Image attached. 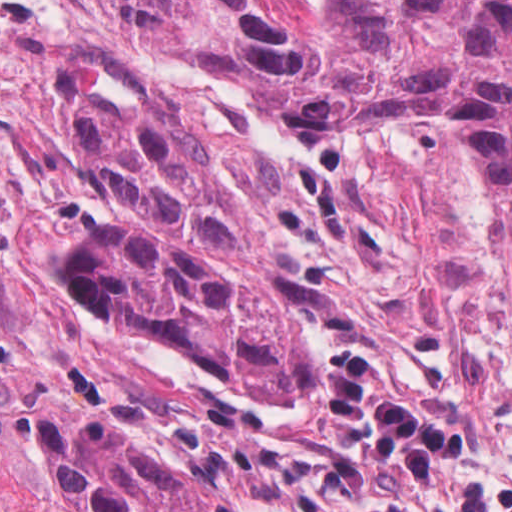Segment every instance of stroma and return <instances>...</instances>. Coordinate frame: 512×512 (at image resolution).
<instances>
[{
	"mask_svg": "<svg viewBox=\"0 0 512 512\" xmlns=\"http://www.w3.org/2000/svg\"><path fill=\"white\" fill-rule=\"evenodd\" d=\"M80 92H164L199 110L285 208L269 253L312 344L305 398L226 386L131 332L223 493L245 512H352L402 499L409 473L370 461L364 428L331 419L315 375L373 356L419 407L474 435L463 487L512 483V323L494 285V216L460 121H388L335 165L259 91L117 36L1 103L83 247L128 227L71 150Z\"/></svg>",
	"mask_w": 512,
	"mask_h": 512,
	"instance_id": "stroma-1",
	"label": "stroma"
}]
</instances>
